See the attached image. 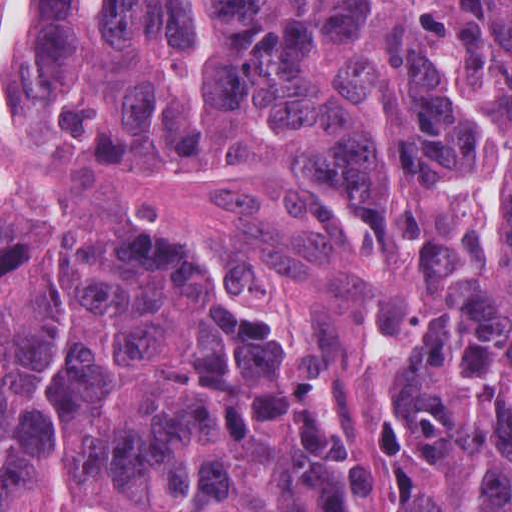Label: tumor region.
Listing matches in <instances>:
<instances>
[{
  "mask_svg": "<svg viewBox=\"0 0 512 512\" xmlns=\"http://www.w3.org/2000/svg\"><path fill=\"white\" fill-rule=\"evenodd\" d=\"M1 139L264 171L370 259L402 512H512V0H13ZM1 512H362L281 319L166 222L1 194Z\"/></svg>",
  "mask_w": 512,
  "mask_h": 512,
  "instance_id": "obj_1",
  "label": "tumor region"
}]
</instances>
